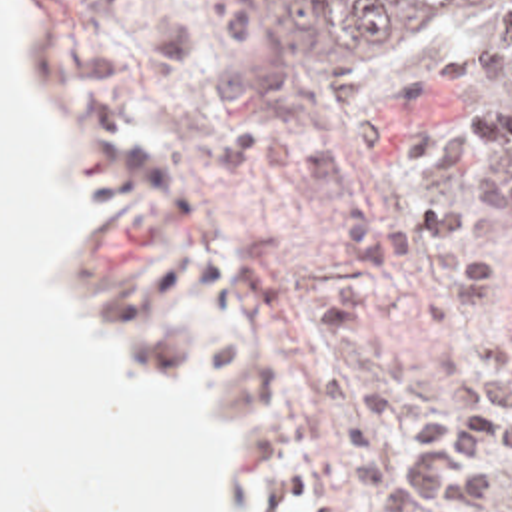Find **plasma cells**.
I'll return each instance as SVG.
<instances>
[{
  "label": "plasma cells",
  "mask_w": 512,
  "mask_h": 512,
  "mask_svg": "<svg viewBox=\"0 0 512 512\" xmlns=\"http://www.w3.org/2000/svg\"><path fill=\"white\" fill-rule=\"evenodd\" d=\"M348 137L352 145L306 153L238 129L220 139L216 161L230 175L298 183L348 205L344 243L370 287L306 313L308 329L342 357L308 359L302 370L350 446V484L372 492L368 512H480L502 484L498 460L512 468V321L492 343V369L440 372L442 390L466 402L456 410L428 406L368 323L390 299L398 269L422 277L424 315L438 333L510 287V273L478 251L470 211L376 185V177H448L482 161L500 139L496 113L480 109L466 125L370 117Z\"/></svg>",
  "instance_id": "1"
}]
</instances>
